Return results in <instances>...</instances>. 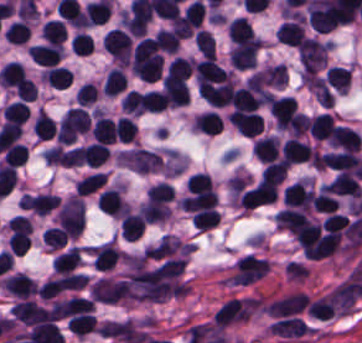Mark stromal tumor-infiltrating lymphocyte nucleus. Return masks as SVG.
I'll return each instance as SVG.
<instances>
[{
	"mask_svg": "<svg viewBox=\"0 0 362 343\" xmlns=\"http://www.w3.org/2000/svg\"><path fill=\"white\" fill-rule=\"evenodd\" d=\"M187 291L179 256L155 243L124 255L117 296L128 301H160Z\"/></svg>",
	"mask_w": 362,
	"mask_h": 343,
	"instance_id": "stromal-tumor-infiltrating-lymphocyte-nucleus-1",
	"label": "stromal tumor-infiltrating lymphocyte nucleus"
},
{
	"mask_svg": "<svg viewBox=\"0 0 362 343\" xmlns=\"http://www.w3.org/2000/svg\"><path fill=\"white\" fill-rule=\"evenodd\" d=\"M327 42L316 38H303L297 51L303 71H317L324 67L328 54Z\"/></svg>",
	"mask_w": 362,
	"mask_h": 343,
	"instance_id": "stromal-tumor-infiltrating-lymphocyte-nucleus-2",
	"label": "stromal tumor-infiltrating lymphocyte nucleus"
},
{
	"mask_svg": "<svg viewBox=\"0 0 362 343\" xmlns=\"http://www.w3.org/2000/svg\"><path fill=\"white\" fill-rule=\"evenodd\" d=\"M276 182L258 180L243 190L239 202V209H252L267 203L274 198Z\"/></svg>",
	"mask_w": 362,
	"mask_h": 343,
	"instance_id": "stromal-tumor-infiltrating-lymphocyte-nucleus-3",
	"label": "stromal tumor-infiltrating lymphocyte nucleus"
},
{
	"mask_svg": "<svg viewBox=\"0 0 362 343\" xmlns=\"http://www.w3.org/2000/svg\"><path fill=\"white\" fill-rule=\"evenodd\" d=\"M296 103L293 96H273L267 105L268 113L274 125L287 128L295 111Z\"/></svg>",
	"mask_w": 362,
	"mask_h": 343,
	"instance_id": "stromal-tumor-infiltrating-lymphocyte-nucleus-4",
	"label": "stromal tumor-infiltrating lymphocyte nucleus"
},
{
	"mask_svg": "<svg viewBox=\"0 0 362 343\" xmlns=\"http://www.w3.org/2000/svg\"><path fill=\"white\" fill-rule=\"evenodd\" d=\"M260 42L249 39L231 49L228 57L233 67L247 69L257 65Z\"/></svg>",
	"mask_w": 362,
	"mask_h": 343,
	"instance_id": "stromal-tumor-infiltrating-lymphocyte-nucleus-5",
	"label": "stromal tumor-infiltrating lymphocyte nucleus"
},
{
	"mask_svg": "<svg viewBox=\"0 0 362 343\" xmlns=\"http://www.w3.org/2000/svg\"><path fill=\"white\" fill-rule=\"evenodd\" d=\"M228 122L244 136H258L263 129V118L255 111L232 110Z\"/></svg>",
	"mask_w": 362,
	"mask_h": 343,
	"instance_id": "stromal-tumor-infiltrating-lymphocyte-nucleus-6",
	"label": "stromal tumor-infiltrating lymphocyte nucleus"
},
{
	"mask_svg": "<svg viewBox=\"0 0 362 343\" xmlns=\"http://www.w3.org/2000/svg\"><path fill=\"white\" fill-rule=\"evenodd\" d=\"M319 163L336 172L357 173L358 157L353 151L320 154Z\"/></svg>",
	"mask_w": 362,
	"mask_h": 343,
	"instance_id": "stromal-tumor-infiltrating-lymphocyte-nucleus-7",
	"label": "stromal tumor-infiltrating lymphocyte nucleus"
},
{
	"mask_svg": "<svg viewBox=\"0 0 362 343\" xmlns=\"http://www.w3.org/2000/svg\"><path fill=\"white\" fill-rule=\"evenodd\" d=\"M329 142L332 147L357 153L361 140L356 130L335 125L332 128Z\"/></svg>",
	"mask_w": 362,
	"mask_h": 343,
	"instance_id": "stromal-tumor-infiltrating-lymphocyte-nucleus-8",
	"label": "stromal tumor-infiltrating lymphocyte nucleus"
},
{
	"mask_svg": "<svg viewBox=\"0 0 362 343\" xmlns=\"http://www.w3.org/2000/svg\"><path fill=\"white\" fill-rule=\"evenodd\" d=\"M280 154L282 159L290 165L309 162L312 150L304 142L290 137L284 141Z\"/></svg>",
	"mask_w": 362,
	"mask_h": 343,
	"instance_id": "stromal-tumor-infiltrating-lymphocyte-nucleus-9",
	"label": "stromal tumor-infiltrating lymphocyte nucleus"
},
{
	"mask_svg": "<svg viewBox=\"0 0 362 343\" xmlns=\"http://www.w3.org/2000/svg\"><path fill=\"white\" fill-rule=\"evenodd\" d=\"M27 54L37 65L56 66L62 55V48L59 44L45 43L34 45Z\"/></svg>",
	"mask_w": 362,
	"mask_h": 343,
	"instance_id": "stromal-tumor-infiltrating-lymphocyte-nucleus-10",
	"label": "stromal tumor-infiltrating lymphocyte nucleus"
},
{
	"mask_svg": "<svg viewBox=\"0 0 362 343\" xmlns=\"http://www.w3.org/2000/svg\"><path fill=\"white\" fill-rule=\"evenodd\" d=\"M251 151L258 160L268 163L278 155L279 141L273 135L257 138L252 143Z\"/></svg>",
	"mask_w": 362,
	"mask_h": 343,
	"instance_id": "stromal-tumor-infiltrating-lymphocyte-nucleus-11",
	"label": "stromal tumor-infiltrating lymphocyte nucleus"
},
{
	"mask_svg": "<svg viewBox=\"0 0 362 343\" xmlns=\"http://www.w3.org/2000/svg\"><path fill=\"white\" fill-rule=\"evenodd\" d=\"M303 32V22L300 18L282 23L275 29V37L279 43L298 46Z\"/></svg>",
	"mask_w": 362,
	"mask_h": 343,
	"instance_id": "stromal-tumor-infiltrating-lymphocyte-nucleus-12",
	"label": "stromal tumor-infiltrating lymphocyte nucleus"
},
{
	"mask_svg": "<svg viewBox=\"0 0 362 343\" xmlns=\"http://www.w3.org/2000/svg\"><path fill=\"white\" fill-rule=\"evenodd\" d=\"M333 125L329 112H321L310 119L309 134L315 141H329Z\"/></svg>",
	"mask_w": 362,
	"mask_h": 343,
	"instance_id": "stromal-tumor-infiltrating-lymphocyte-nucleus-13",
	"label": "stromal tumor-infiltrating lymphocyte nucleus"
},
{
	"mask_svg": "<svg viewBox=\"0 0 362 343\" xmlns=\"http://www.w3.org/2000/svg\"><path fill=\"white\" fill-rule=\"evenodd\" d=\"M81 253L82 249L70 247L51 262L53 270L62 276L71 273L77 267Z\"/></svg>",
	"mask_w": 362,
	"mask_h": 343,
	"instance_id": "stromal-tumor-infiltrating-lymphocyte-nucleus-14",
	"label": "stromal tumor-infiltrating lymphocyte nucleus"
},
{
	"mask_svg": "<svg viewBox=\"0 0 362 343\" xmlns=\"http://www.w3.org/2000/svg\"><path fill=\"white\" fill-rule=\"evenodd\" d=\"M330 193L360 196L362 191L358 180L352 174L337 173L331 183Z\"/></svg>",
	"mask_w": 362,
	"mask_h": 343,
	"instance_id": "stromal-tumor-infiltrating-lymphocyte-nucleus-15",
	"label": "stromal tumor-infiltrating lymphocyte nucleus"
},
{
	"mask_svg": "<svg viewBox=\"0 0 362 343\" xmlns=\"http://www.w3.org/2000/svg\"><path fill=\"white\" fill-rule=\"evenodd\" d=\"M325 79L336 92L346 93L351 81V71L345 66L331 65L325 71Z\"/></svg>",
	"mask_w": 362,
	"mask_h": 343,
	"instance_id": "stromal-tumor-infiltrating-lymphocyte-nucleus-16",
	"label": "stromal tumor-infiltrating lymphocyte nucleus"
},
{
	"mask_svg": "<svg viewBox=\"0 0 362 343\" xmlns=\"http://www.w3.org/2000/svg\"><path fill=\"white\" fill-rule=\"evenodd\" d=\"M143 226L140 215L129 211L121 220L119 234L127 241H136L142 234Z\"/></svg>",
	"mask_w": 362,
	"mask_h": 343,
	"instance_id": "stromal-tumor-infiltrating-lymphocyte-nucleus-17",
	"label": "stromal tumor-infiltrating lymphocyte nucleus"
},
{
	"mask_svg": "<svg viewBox=\"0 0 362 343\" xmlns=\"http://www.w3.org/2000/svg\"><path fill=\"white\" fill-rule=\"evenodd\" d=\"M223 122L220 116L211 111L200 112L194 119V127L197 132L216 135L222 129Z\"/></svg>",
	"mask_w": 362,
	"mask_h": 343,
	"instance_id": "stromal-tumor-infiltrating-lymphocyte-nucleus-18",
	"label": "stromal tumor-infiltrating lymphocyte nucleus"
},
{
	"mask_svg": "<svg viewBox=\"0 0 362 343\" xmlns=\"http://www.w3.org/2000/svg\"><path fill=\"white\" fill-rule=\"evenodd\" d=\"M91 138L99 143L115 142L114 125L108 116L97 115L92 125Z\"/></svg>",
	"mask_w": 362,
	"mask_h": 343,
	"instance_id": "stromal-tumor-infiltrating-lymphocyte-nucleus-19",
	"label": "stromal tumor-infiltrating lymphocyte nucleus"
},
{
	"mask_svg": "<svg viewBox=\"0 0 362 343\" xmlns=\"http://www.w3.org/2000/svg\"><path fill=\"white\" fill-rule=\"evenodd\" d=\"M230 39L236 44L255 39V35L247 21L242 17H235L226 27Z\"/></svg>",
	"mask_w": 362,
	"mask_h": 343,
	"instance_id": "stromal-tumor-infiltrating-lymphocyte-nucleus-20",
	"label": "stromal tumor-infiltrating lymphocyte nucleus"
},
{
	"mask_svg": "<svg viewBox=\"0 0 362 343\" xmlns=\"http://www.w3.org/2000/svg\"><path fill=\"white\" fill-rule=\"evenodd\" d=\"M42 37L46 43H62L66 31L65 27L59 19H46L41 31Z\"/></svg>",
	"mask_w": 362,
	"mask_h": 343,
	"instance_id": "stromal-tumor-infiltrating-lymphocyte-nucleus-21",
	"label": "stromal tumor-infiltrating lymphocyte nucleus"
},
{
	"mask_svg": "<svg viewBox=\"0 0 362 343\" xmlns=\"http://www.w3.org/2000/svg\"><path fill=\"white\" fill-rule=\"evenodd\" d=\"M126 87L125 76L118 68H111L104 78L103 91L107 96H115Z\"/></svg>",
	"mask_w": 362,
	"mask_h": 343,
	"instance_id": "stromal-tumor-infiltrating-lymphocyte-nucleus-22",
	"label": "stromal tumor-infiltrating lymphocyte nucleus"
},
{
	"mask_svg": "<svg viewBox=\"0 0 362 343\" xmlns=\"http://www.w3.org/2000/svg\"><path fill=\"white\" fill-rule=\"evenodd\" d=\"M106 180L102 172H94L84 176L73 184L75 194L87 195L100 188Z\"/></svg>",
	"mask_w": 362,
	"mask_h": 343,
	"instance_id": "stromal-tumor-infiltrating-lymphocyte-nucleus-23",
	"label": "stromal tumor-infiltrating lymphocyte nucleus"
},
{
	"mask_svg": "<svg viewBox=\"0 0 362 343\" xmlns=\"http://www.w3.org/2000/svg\"><path fill=\"white\" fill-rule=\"evenodd\" d=\"M186 186L191 193L213 194L211 178L209 174L203 172L190 174Z\"/></svg>",
	"mask_w": 362,
	"mask_h": 343,
	"instance_id": "stromal-tumor-infiltrating-lymphocyte-nucleus-24",
	"label": "stromal tumor-infiltrating lymphocyte nucleus"
},
{
	"mask_svg": "<svg viewBox=\"0 0 362 343\" xmlns=\"http://www.w3.org/2000/svg\"><path fill=\"white\" fill-rule=\"evenodd\" d=\"M32 131L37 138H51L56 133L53 121L45 112H37L33 122Z\"/></svg>",
	"mask_w": 362,
	"mask_h": 343,
	"instance_id": "stromal-tumor-infiltrating-lymphocyte-nucleus-25",
	"label": "stromal tumor-infiltrating lymphocyte nucleus"
},
{
	"mask_svg": "<svg viewBox=\"0 0 362 343\" xmlns=\"http://www.w3.org/2000/svg\"><path fill=\"white\" fill-rule=\"evenodd\" d=\"M154 40L159 48L165 54H175L180 39L170 29H159L155 34Z\"/></svg>",
	"mask_w": 362,
	"mask_h": 343,
	"instance_id": "stromal-tumor-infiltrating-lymphocyte-nucleus-26",
	"label": "stromal tumor-infiltrating lymphocyte nucleus"
},
{
	"mask_svg": "<svg viewBox=\"0 0 362 343\" xmlns=\"http://www.w3.org/2000/svg\"><path fill=\"white\" fill-rule=\"evenodd\" d=\"M47 250L58 251L66 245V238L62 229L57 226H50L41 239Z\"/></svg>",
	"mask_w": 362,
	"mask_h": 343,
	"instance_id": "stromal-tumor-infiltrating-lymphocyte-nucleus-27",
	"label": "stromal tumor-infiltrating lymphocyte nucleus"
},
{
	"mask_svg": "<svg viewBox=\"0 0 362 343\" xmlns=\"http://www.w3.org/2000/svg\"><path fill=\"white\" fill-rule=\"evenodd\" d=\"M115 137L120 142H129L134 139L136 134V126L126 116H119L114 122Z\"/></svg>",
	"mask_w": 362,
	"mask_h": 343,
	"instance_id": "stromal-tumor-infiltrating-lymphocyte-nucleus-28",
	"label": "stromal tumor-infiltrating lymphocyte nucleus"
},
{
	"mask_svg": "<svg viewBox=\"0 0 362 343\" xmlns=\"http://www.w3.org/2000/svg\"><path fill=\"white\" fill-rule=\"evenodd\" d=\"M219 220L216 210L206 209L192 214L191 223L200 231H207L213 227Z\"/></svg>",
	"mask_w": 362,
	"mask_h": 343,
	"instance_id": "stromal-tumor-infiltrating-lymphocyte-nucleus-29",
	"label": "stromal tumor-infiltrating lymphocyte nucleus"
},
{
	"mask_svg": "<svg viewBox=\"0 0 362 343\" xmlns=\"http://www.w3.org/2000/svg\"><path fill=\"white\" fill-rule=\"evenodd\" d=\"M94 42L91 36L84 32H77L72 37L71 49L78 55L92 54Z\"/></svg>",
	"mask_w": 362,
	"mask_h": 343,
	"instance_id": "stromal-tumor-infiltrating-lymphocyte-nucleus-30",
	"label": "stromal tumor-infiltrating lymphocyte nucleus"
},
{
	"mask_svg": "<svg viewBox=\"0 0 362 343\" xmlns=\"http://www.w3.org/2000/svg\"><path fill=\"white\" fill-rule=\"evenodd\" d=\"M286 175V164L281 159L270 164H267L261 173L262 179L281 182Z\"/></svg>",
	"mask_w": 362,
	"mask_h": 343,
	"instance_id": "stromal-tumor-infiltrating-lymphocyte-nucleus-31",
	"label": "stromal tumor-infiltrating lymphocyte nucleus"
},
{
	"mask_svg": "<svg viewBox=\"0 0 362 343\" xmlns=\"http://www.w3.org/2000/svg\"><path fill=\"white\" fill-rule=\"evenodd\" d=\"M195 45L201 55L214 57V39L206 29L196 32Z\"/></svg>",
	"mask_w": 362,
	"mask_h": 343,
	"instance_id": "stromal-tumor-infiltrating-lymphocyte-nucleus-32",
	"label": "stromal tumor-infiltrating lymphocyte nucleus"
}]
</instances>
